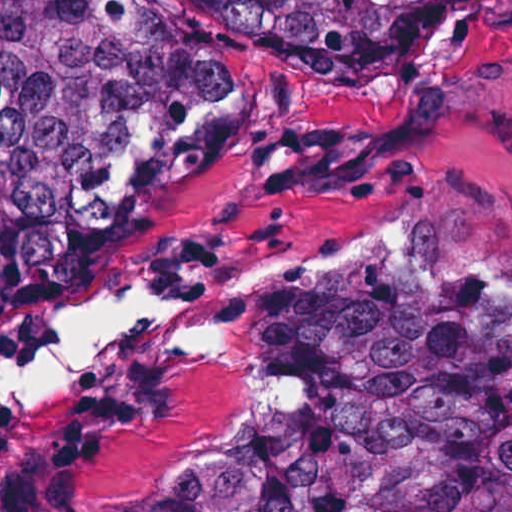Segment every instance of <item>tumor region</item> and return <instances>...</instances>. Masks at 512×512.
I'll list each match as a JSON object with an SVG mask.
<instances>
[{
	"mask_svg": "<svg viewBox=\"0 0 512 512\" xmlns=\"http://www.w3.org/2000/svg\"><path fill=\"white\" fill-rule=\"evenodd\" d=\"M199 1L282 50L388 71L497 0ZM243 112L241 82L151 0H0V325L69 305L98 237L224 154ZM390 256L249 309V350L295 406L150 512H512V296L419 235Z\"/></svg>",
	"mask_w": 512,
	"mask_h": 512,
	"instance_id": "obj_1",
	"label": "tumor region"
}]
</instances>
